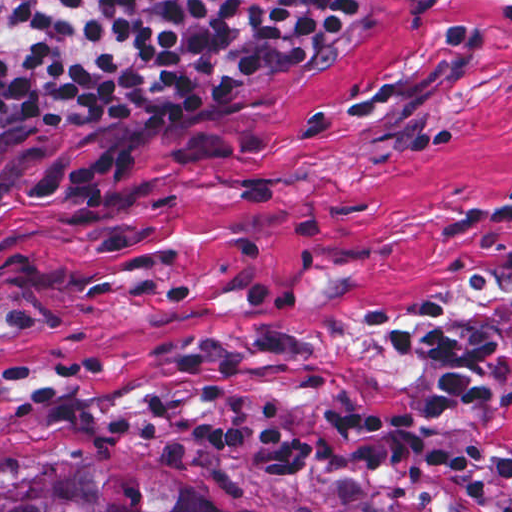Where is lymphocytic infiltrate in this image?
I'll return each instance as SVG.
<instances>
[{"label":"lymphocytic infiltrate","mask_w":512,"mask_h":512,"mask_svg":"<svg viewBox=\"0 0 512 512\" xmlns=\"http://www.w3.org/2000/svg\"><path fill=\"white\" fill-rule=\"evenodd\" d=\"M367 7V0H0V132L241 94L316 57ZM383 347L434 368L431 403L334 413L312 430L274 432L268 417L231 420L228 387L201 381L194 423L170 400L149 395L136 414L112 415L104 425L194 445L255 474L463 477L462 493L474 501H485L491 472L512 500V458L493 461L489 451L438 442L503 397L497 385L465 373L444 309L418 305Z\"/></svg>","instance_id":"obj_1"}]
</instances>
